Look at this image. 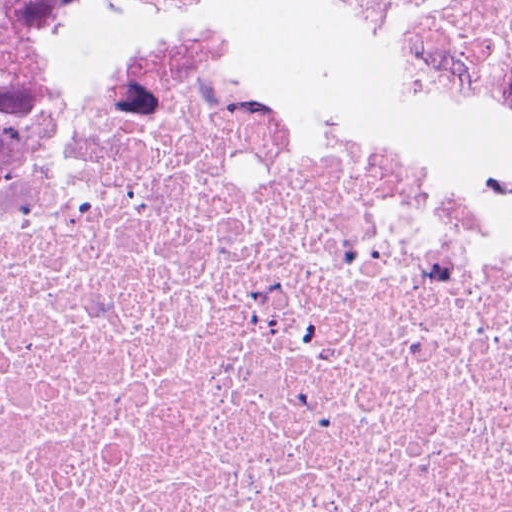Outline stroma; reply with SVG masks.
I'll return each instance as SVG.
<instances>
[{"mask_svg": "<svg viewBox=\"0 0 512 512\" xmlns=\"http://www.w3.org/2000/svg\"><path fill=\"white\" fill-rule=\"evenodd\" d=\"M232 43L512 181V95L479 55L369 0H209Z\"/></svg>", "mask_w": 512, "mask_h": 512, "instance_id": "1", "label": "stroma"}]
</instances>
